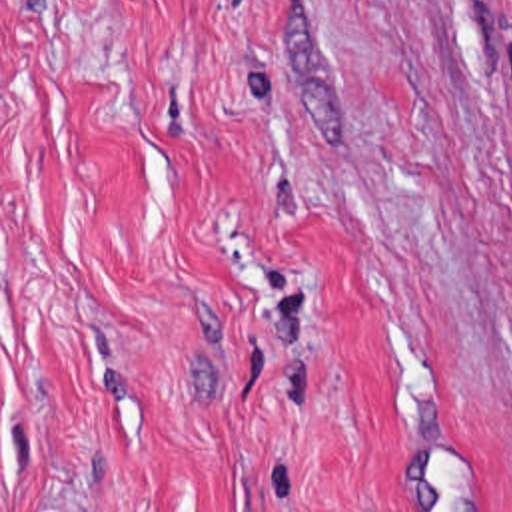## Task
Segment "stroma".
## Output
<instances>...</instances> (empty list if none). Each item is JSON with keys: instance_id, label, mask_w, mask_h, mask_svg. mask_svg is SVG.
<instances>
[{"instance_id": "35a3bbf8", "label": "stroma", "mask_w": 512, "mask_h": 512, "mask_svg": "<svg viewBox=\"0 0 512 512\" xmlns=\"http://www.w3.org/2000/svg\"><path fill=\"white\" fill-rule=\"evenodd\" d=\"M0 512H512V0H0Z\"/></svg>"}]
</instances>
